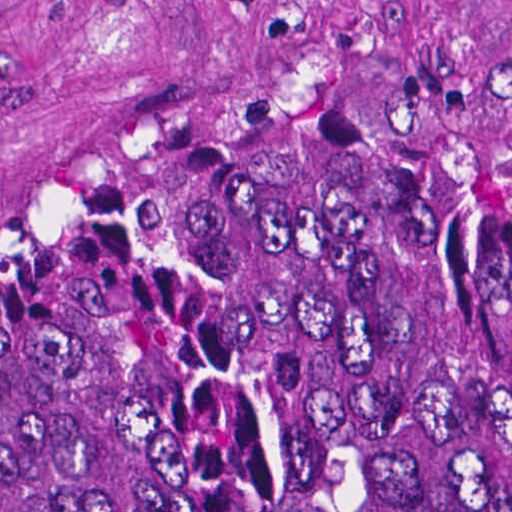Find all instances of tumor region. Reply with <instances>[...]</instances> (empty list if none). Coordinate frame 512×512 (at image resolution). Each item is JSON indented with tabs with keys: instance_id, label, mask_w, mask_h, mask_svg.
Returning <instances> with one entry per match:
<instances>
[{
	"instance_id": "e687c5a6",
	"label": "tumor region",
	"mask_w": 512,
	"mask_h": 512,
	"mask_svg": "<svg viewBox=\"0 0 512 512\" xmlns=\"http://www.w3.org/2000/svg\"><path fill=\"white\" fill-rule=\"evenodd\" d=\"M0 512H512V175L408 111L155 156L0 272Z\"/></svg>"
}]
</instances>
